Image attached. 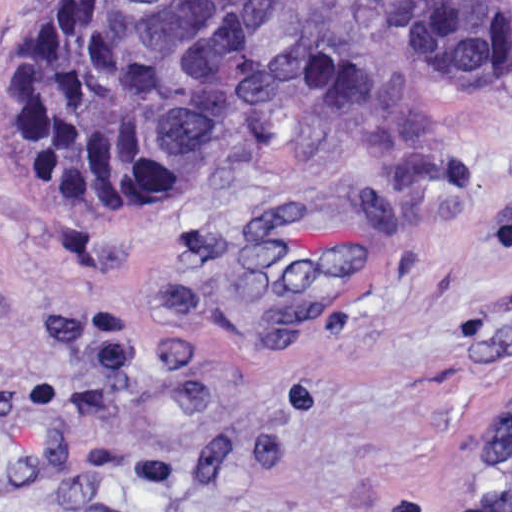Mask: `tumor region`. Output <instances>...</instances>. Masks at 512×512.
<instances>
[{
	"label": "tumor region",
	"instance_id": "e687c5a6",
	"mask_svg": "<svg viewBox=\"0 0 512 512\" xmlns=\"http://www.w3.org/2000/svg\"><path fill=\"white\" fill-rule=\"evenodd\" d=\"M410 57L472 83L512 69L505 0H419ZM242 104L217 0H19L3 28L1 136L12 164L107 229L216 163ZM470 512H512V392L470 460Z\"/></svg>",
	"mask_w": 512,
	"mask_h": 512
}]
</instances>
